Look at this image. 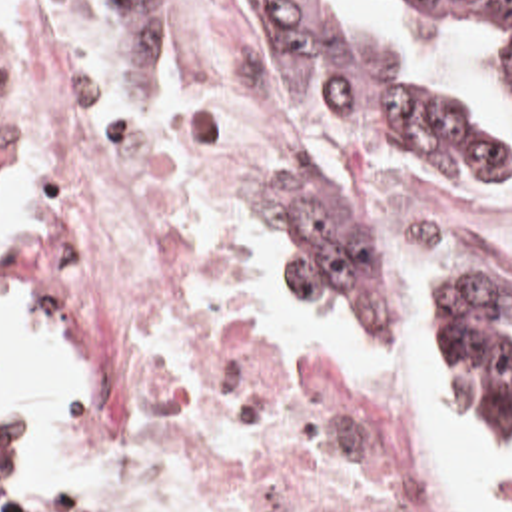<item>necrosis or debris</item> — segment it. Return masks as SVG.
Segmentation results:
<instances>
[{"instance_id": "1", "label": "necrosis or debris", "mask_w": 512, "mask_h": 512, "mask_svg": "<svg viewBox=\"0 0 512 512\" xmlns=\"http://www.w3.org/2000/svg\"><path fill=\"white\" fill-rule=\"evenodd\" d=\"M179 33L0 49V193L39 197L33 267L103 338L95 418L239 508L428 512L267 402L243 269L289 75L247 21L211 11ZM305 171L377 211L401 305L462 253L512 269V201L448 195L317 139Z\"/></svg>"}]
</instances>
